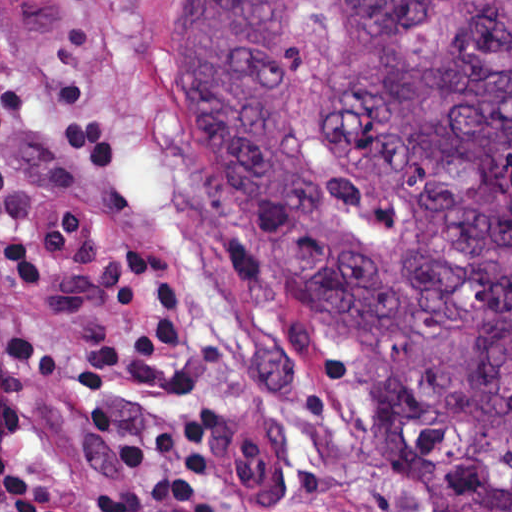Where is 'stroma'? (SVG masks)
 I'll use <instances>...</instances> for the list:
<instances>
[{"mask_svg":"<svg viewBox=\"0 0 512 512\" xmlns=\"http://www.w3.org/2000/svg\"><path fill=\"white\" fill-rule=\"evenodd\" d=\"M158 0H0L1 450L73 501L114 473L82 412L85 354L154 363L205 424L198 512H422L391 463L390 369L263 276L206 137L155 83ZM280 429L255 501L227 494L216 419Z\"/></svg>","mask_w":512,"mask_h":512,"instance_id":"35a3bbf8","label":"stroma"}]
</instances>
